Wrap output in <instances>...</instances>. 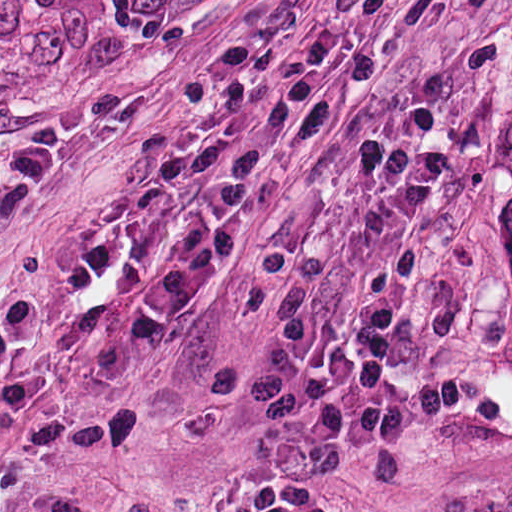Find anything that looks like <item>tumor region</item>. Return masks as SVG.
<instances>
[{
	"label": "tumor region",
	"instance_id": "1",
	"mask_svg": "<svg viewBox=\"0 0 512 512\" xmlns=\"http://www.w3.org/2000/svg\"><path fill=\"white\" fill-rule=\"evenodd\" d=\"M476 209L491 246L512 262V127L476 170Z\"/></svg>",
	"mask_w": 512,
	"mask_h": 512
}]
</instances>
